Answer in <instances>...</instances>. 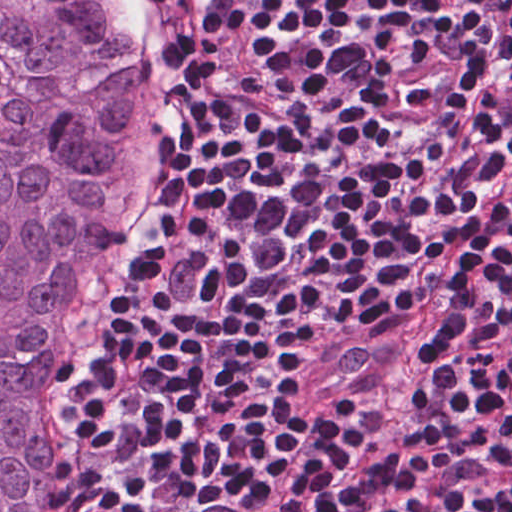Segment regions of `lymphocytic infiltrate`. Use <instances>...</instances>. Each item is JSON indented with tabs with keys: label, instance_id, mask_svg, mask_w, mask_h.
Wrapping results in <instances>:
<instances>
[{
	"label": "lymphocytic infiltrate",
	"instance_id": "1",
	"mask_svg": "<svg viewBox=\"0 0 512 512\" xmlns=\"http://www.w3.org/2000/svg\"><path fill=\"white\" fill-rule=\"evenodd\" d=\"M155 2L66 512H512V0Z\"/></svg>",
	"mask_w": 512,
	"mask_h": 512
}]
</instances>
